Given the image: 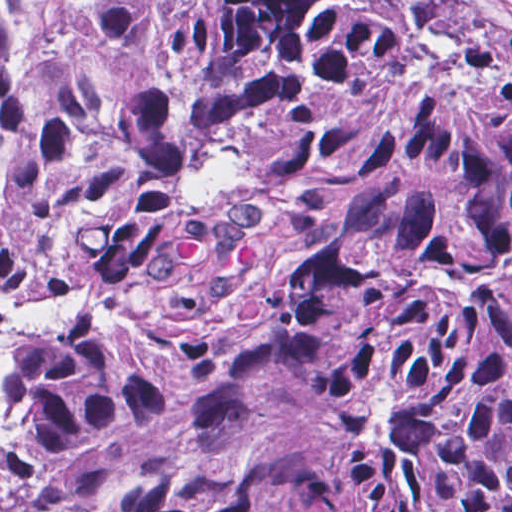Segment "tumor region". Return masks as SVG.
Masks as SVG:
<instances>
[{"label": "tumor region", "mask_w": 512, "mask_h": 512, "mask_svg": "<svg viewBox=\"0 0 512 512\" xmlns=\"http://www.w3.org/2000/svg\"><path fill=\"white\" fill-rule=\"evenodd\" d=\"M0 512H512V9L0 0Z\"/></svg>", "instance_id": "tumor-region-1"}]
</instances>
